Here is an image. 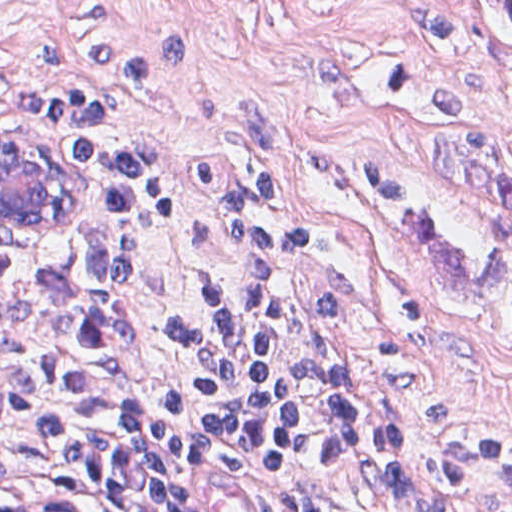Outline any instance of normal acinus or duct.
<instances>
[{
    "label": "normal acinus or duct",
    "instance_id": "obj_1",
    "mask_svg": "<svg viewBox=\"0 0 512 512\" xmlns=\"http://www.w3.org/2000/svg\"><path fill=\"white\" fill-rule=\"evenodd\" d=\"M73 189V175L50 152L0 127V210L44 217ZM0 512H63L33 499L17 476L0 477Z\"/></svg>",
    "mask_w": 512,
    "mask_h": 512
}]
</instances>
